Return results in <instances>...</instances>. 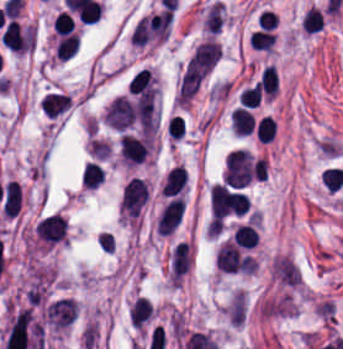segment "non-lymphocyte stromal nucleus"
Instances as JSON below:
<instances>
[{
    "mask_svg": "<svg viewBox=\"0 0 343 349\" xmlns=\"http://www.w3.org/2000/svg\"><path fill=\"white\" fill-rule=\"evenodd\" d=\"M79 310L75 298L59 297L46 308V319L52 328L62 329L71 323Z\"/></svg>",
    "mask_w": 343,
    "mask_h": 349,
    "instance_id": "a72fc3eb",
    "label": "non-lymphocyte stromal nucleus"
},
{
    "mask_svg": "<svg viewBox=\"0 0 343 349\" xmlns=\"http://www.w3.org/2000/svg\"><path fill=\"white\" fill-rule=\"evenodd\" d=\"M211 66L212 65L195 50L179 79L175 101L187 103L207 76Z\"/></svg>",
    "mask_w": 343,
    "mask_h": 349,
    "instance_id": "dd21d789",
    "label": "non-lymphocyte stromal nucleus"
},
{
    "mask_svg": "<svg viewBox=\"0 0 343 349\" xmlns=\"http://www.w3.org/2000/svg\"><path fill=\"white\" fill-rule=\"evenodd\" d=\"M191 265L190 244L179 241L169 255L168 278L170 282H180Z\"/></svg>",
    "mask_w": 343,
    "mask_h": 349,
    "instance_id": "3746e769",
    "label": "non-lymphocyte stromal nucleus"
}]
</instances>
